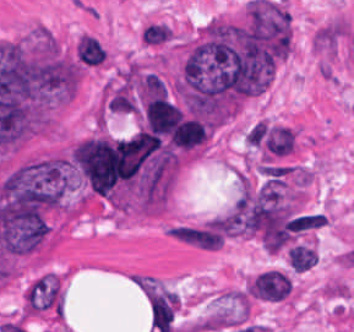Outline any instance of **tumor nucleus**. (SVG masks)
I'll use <instances>...</instances> for the list:
<instances>
[{
  "instance_id": "tumor-nucleus-1",
  "label": "tumor nucleus",
  "mask_w": 354,
  "mask_h": 332,
  "mask_svg": "<svg viewBox=\"0 0 354 332\" xmlns=\"http://www.w3.org/2000/svg\"><path fill=\"white\" fill-rule=\"evenodd\" d=\"M22 301L31 313H59L63 298L57 278L47 273L37 278L25 289Z\"/></svg>"
},
{
  "instance_id": "tumor-nucleus-2",
  "label": "tumor nucleus",
  "mask_w": 354,
  "mask_h": 332,
  "mask_svg": "<svg viewBox=\"0 0 354 332\" xmlns=\"http://www.w3.org/2000/svg\"><path fill=\"white\" fill-rule=\"evenodd\" d=\"M292 288L291 278L280 269H267L253 277L247 296L257 301H282Z\"/></svg>"
},
{
  "instance_id": "tumor-nucleus-3",
  "label": "tumor nucleus",
  "mask_w": 354,
  "mask_h": 332,
  "mask_svg": "<svg viewBox=\"0 0 354 332\" xmlns=\"http://www.w3.org/2000/svg\"><path fill=\"white\" fill-rule=\"evenodd\" d=\"M75 57L85 67H98L107 58L106 48L95 36L84 34L76 42Z\"/></svg>"
},
{
  "instance_id": "tumor-nucleus-4",
  "label": "tumor nucleus",
  "mask_w": 354,
  "mask_h": 332,
  "mask_svg": "<svg viewBox=\"0 0 354 332\" xmlns=\"http://www.w3.org/2000/svg\"><path fill=\"white\" fill-rule=\"evenodd\" d=\"M295 136L290 127L273 126L267 135V148L275 156H282L294 149Z\"/></svg>"
},
{
  "instance_id": "tumor-nucleus-5",
  "label": "tumor nucleus",
  "mask_w": 354,
  "mask_h": 332,
  "mask_svg": "<svg viewBox=\"0 0 354 332\" xmlns=\"http://www.w3.org/2000/svg\"><path fill=\"white\" fill-rule=\"evenodd\" d=\"M171 38V29L160 21L148 23L140 31V42L145 46H158Z\"/></svg>"
},
{
  "instance_id": "tumor-nucleus-6",
  "label": "tumor nucleus",
  "mask_w": 354,
  "mask_h": 332,
  "mask_svg": "<svg viewBox=\"0 0 354 332\" xmlns=\"http://www.w3.org/2000/svg\"><path fill=\"white\" fill-rule=\"evenodd\" d=\"M316 253L317 251L305 245L291 248L288 252V263L296 272H305L312 268Z\"/></svg>"
}]
</instances>
